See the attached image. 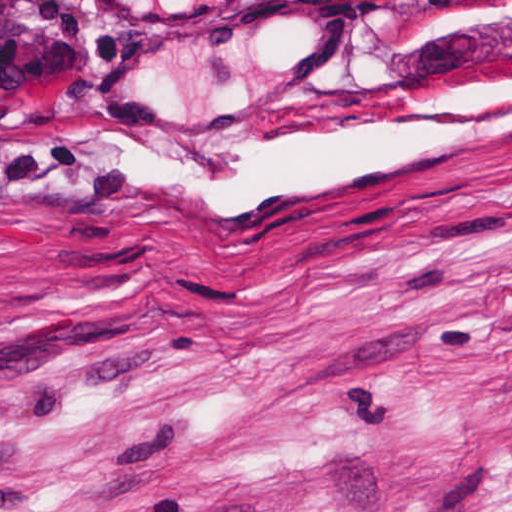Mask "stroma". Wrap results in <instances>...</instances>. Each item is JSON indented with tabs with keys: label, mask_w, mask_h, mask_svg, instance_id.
Masks as SVG:
<instances>
[{
	"label": "stroma",
	"mask_w": 512,
	"mask_h": 512,
	"mask_svg": "<svg viewBox=\"0 0 512 512\" xmlns=\"http://www.w3.org/2000/svg\"><path fill=\"white\" fill-rule=\"evenodd\" d=\"M0 512H512V0H0Z\"/></svg>",
	"instance_id": "1"
}]
</instances>
